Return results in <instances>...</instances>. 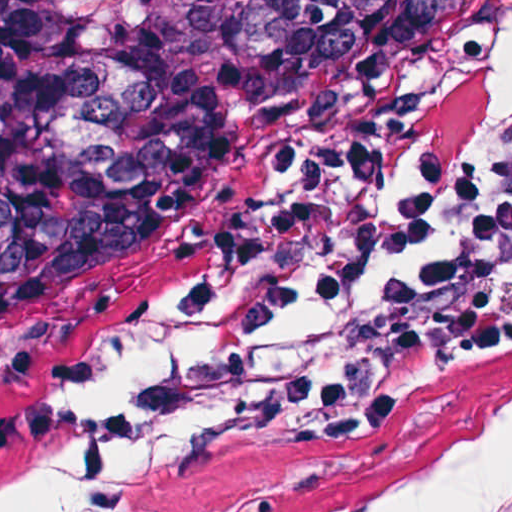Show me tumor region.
I'll return each instance as SVG.
<instances>
[{"instance_id":"e687c5a6","label":"tumor region","mask_w":512,"mask_h":512,"mask_svg":"<svg viewBox=\"0 0 512 512\" xmlns=\"http://www.w3.org/2000/svg\"><path fill=\"white\" fill-rule=\"evenodd\" d=\"M497 0H0V401L218 223L410 124Z\"/></svg>"}]
</instances>
